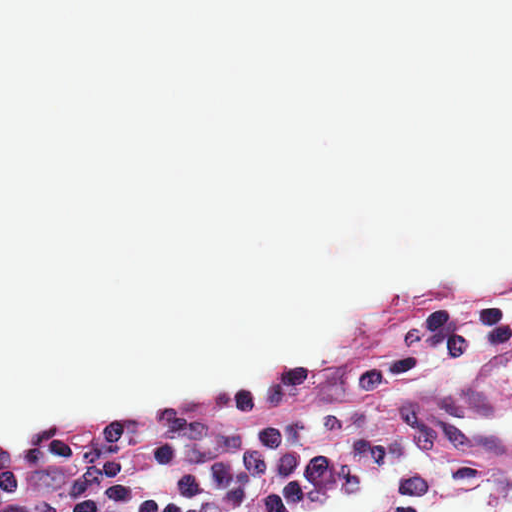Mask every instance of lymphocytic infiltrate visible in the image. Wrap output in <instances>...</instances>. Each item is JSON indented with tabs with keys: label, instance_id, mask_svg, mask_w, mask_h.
<instances>
[{
	"label": "lymphocytic infiltrate",
	"instance_id": "lymphocytic-infiltrate-1",
	"mask_svg": "<svg viewBox=\"0 0 512 512\" xmlns=\"http://www.w3.org/2000/svg\"><path fill=\"white\" fill-rule=\"evenodd\" d=\"M508 347L512 279L399 290L345 340L281 370L33 427L0 448V512H300L414 464V443L381 425L384 408Z\"/></svg>",
	"mask_w": 512,
	"mask_h": 512
}]
</instances>
